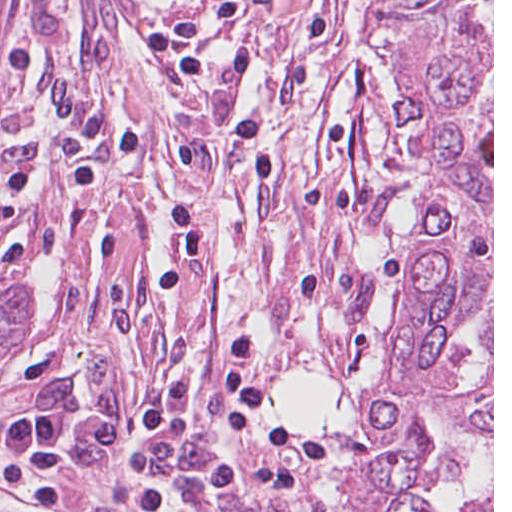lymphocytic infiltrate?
<instances>
[{
	"label": "lymphocytic infiltrate",
	"instance_id": "1",
	"mask_svg": "<svg viewBox=\"0 0 512 512\" xmlns=\"http://www.w3.org/2000/svg\"><path fill=\"white\" fill-rule=\"evenodd\" d=\"M171 217L178 246L155 273V294L174 290L207 256L206 231L189 201L178 204ZM256 350V339L249 332L236 334L224 345L219 356L221 419L230 434L266 442L272 448L266 463L175 469L168 435L190 397L189 380L176 378L156 386L110 423L83 429L75 425L73 409L63 406L13 418L0 428V486L20 512H110L94 501L72 497L71 457L86 466L115 455L138 436H146L152 447L137 485L145 512H177L172 506V483L194 492L225 493L292 486L299 470L294 455L297 439L264 427L270 394L252 371Z\"/></svg>",
	"mask_w": 512,
	"mask_h": 512
}]
</instances>
